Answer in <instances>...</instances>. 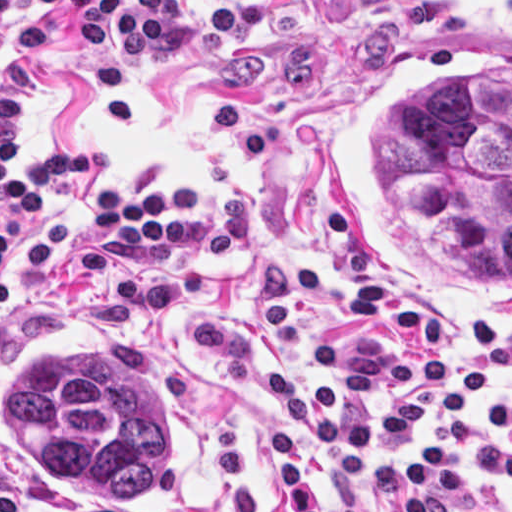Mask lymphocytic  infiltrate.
<instances>
[{
    "label": "lymphocytic infiltrate",
    "instance_id": "f902f5d3",
    "mask_svg": "<svg viewBox=\"0 0 512 512\" xmlns=\"http://www.w3.org/2000/svg\"><path fill=\"white\" fill-rule=\"evenodd\" d=\"M55 12L67 38L80 46L114 47L130 56L163 45L187 14L183 0H0V56L9 66L45 48ZM27 106L22 87L0 70V213L14 225L40 210L35 198L43 192L105 172L116 157L111 145L41 149L27 174L8 153L10 134L25 119ZM96 221L116 242L184 235V215L159 189L140 200L116 189L106 192L96 205ZM75 243L76 221L59 213L41 214L19 233L0 223V314L13 299V271H47ZM190 342L224 367L235 387L293 416L315 434L342 512H365V490L388 498L392 512H499L467 497L441 444L417 446L411 470L391 456L367 453L369 445L405 444L410 430L428 422L421 397L393 396L374 412L336 406L399 387L445 386L441 412L449 419H462L470 400L482 392L479 407L494 427L486 420L465 424L469 452L488 475L512 486V389H486V373L460 354L404 356L387 348L355 353L337 343H319L310 352L312 364L341 382L303 388L257 368L244 344L227 333L190 332ZM273 446L282 489L296 512H324L304 466L299 432L278 425ZM16 511L18 483L0 450V512Z\"/></svg>",
    "mask_w": 512,
    "mask_h": 512
}]
</instances>
